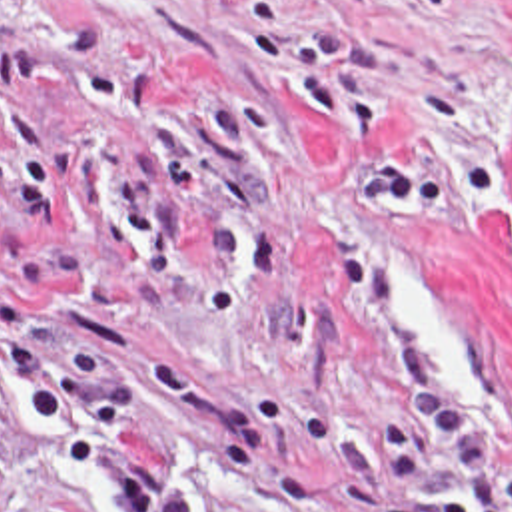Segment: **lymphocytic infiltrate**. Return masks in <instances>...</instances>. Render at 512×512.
<instances>
[{"label":"lymphocytic infiltrate","instance_id":"lymphocytic-infiltrate-1","mask_svg":"<svg viewBox=\"0 0 512 512\" xmlns=\"http://www.w3.org/2000/svg\"><path fill=\"white\" fill-rule=\"evenodd\" d=\"M374 327L394 349V414L378 428L386 482L398 484L414 468L440 480L436 502H418L380 490L374 482L346 484L332 496L336 512H512V476L490 488L482 456L442 392L434 368L404 321V285L398 273L366 259L344 267Z\"/></svg>","mask_w":512,"mask_h":512}]
</instances>
